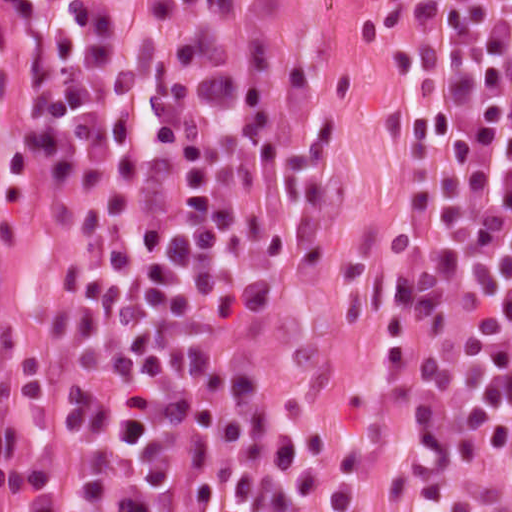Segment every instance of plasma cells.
<instances>
[{
	"mask_svg": "<svg viewBox=\"0 0 512 512\" xmlns=\"http://www.w3.org/2000/svg\"><path fill=\"white\" fill-rule=\"evenodd\" d=\"M495 52L408 104L411 229L384 360V453L421 492L512 463V84ZM32 222L67 273L0 336V512H242L277 431L234 343L237 299L293 236V181L234 67L117 47L21 90Z\"/></svg>",
	"mask_w": 512,
	"mask_h": 512,
	"instance_id": "1",
	"label": "plasma cells"
}]
</instances>
